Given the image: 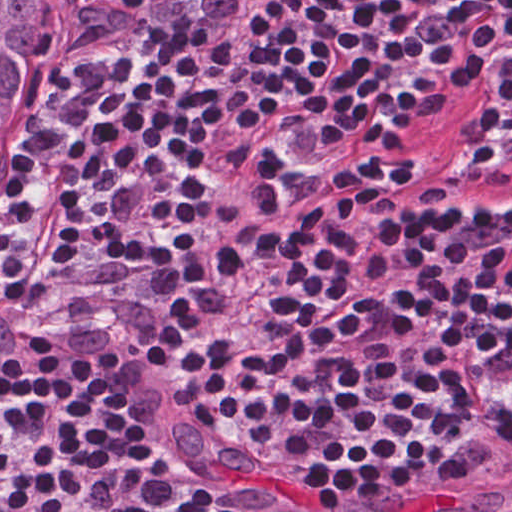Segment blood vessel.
<instances>
[{"mask_svg": "<svg viewBox=\"0 0 512 512\" xmlns=\"http://www.w3.org/2000/svg\"><path fill=\"white\" fill-rule=\"evenodd\" d=\"M430 476L416 485L333 512H512V484Z\"/></svg>", "mask_w": 512, "mask_h": 512, "instance_id": "8fb6f2fc", "label": "blood vessel"}]
</instances>
